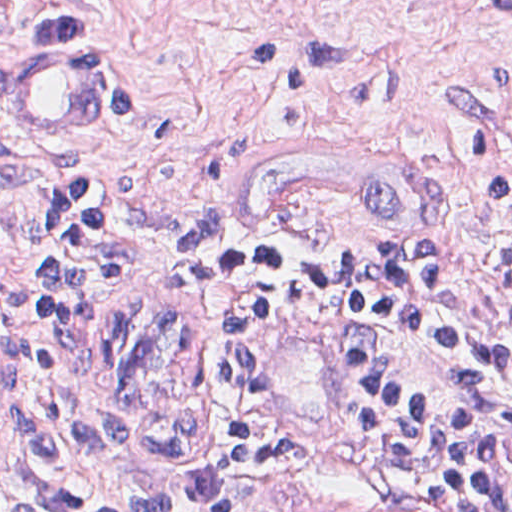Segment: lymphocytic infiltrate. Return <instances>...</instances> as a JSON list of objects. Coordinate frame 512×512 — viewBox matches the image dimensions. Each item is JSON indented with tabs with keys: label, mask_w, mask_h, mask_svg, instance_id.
<instances>
[{
	"label": "lymphocytic infiltrate",
	"mask_w": 512,
	"mask_h": 512,
	"mask_svg": "<svg viewBox=\"0 0 512 512\" xmlns=\"http://www.w3.org/2000/svg\"><path fill=\"white\" fill-rule=\"evenodd\" d=\"M489 186L512 204V166ZM177 206L101 185L58 198L32 266L0 288L25 402L81 512H283L307 479L265 424L262 387L292 319L331 329L354 415L383 459L453 512H512V245L286 262L211 259L208 383L143 415L113 391L100 317L117 284L175 267Z\"/></svg>",
	"instance_id": "f902f5d3"
}]
</instances>
